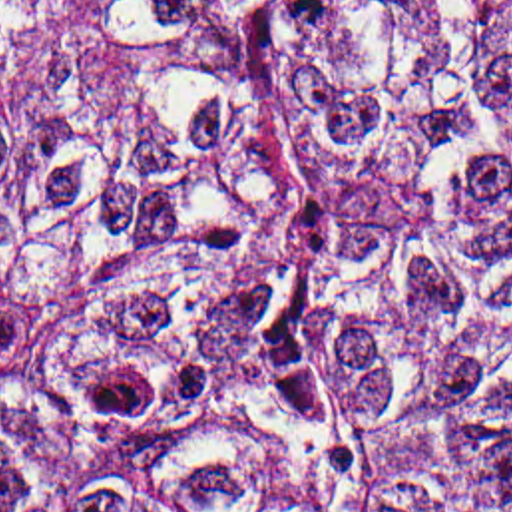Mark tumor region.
Listing matches in <instances>:
<instances>
[{
  "label": "tumor region",
  "instance_id": "1",
  "mask_svg": "<svg viewBox=\"0 0 512 512\" xmlns=\"http://www.w3.org/2000/svg\"><path fill=\"white\" fill-rule=\"evenodd\" d=\"M0 512H512V0H0Z\"/></svg>",
  "mask_w": 512,
  "mask_h": 512
}]
</instances>
